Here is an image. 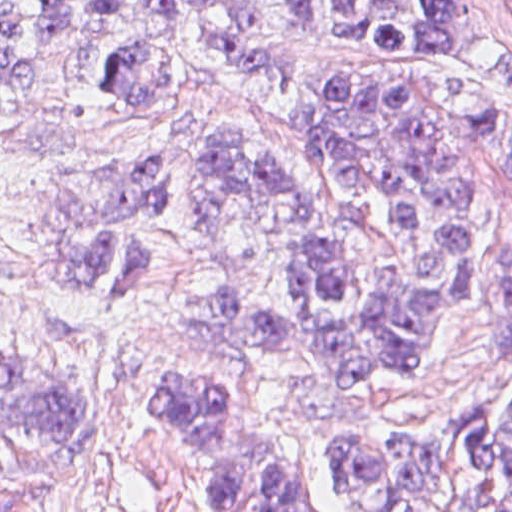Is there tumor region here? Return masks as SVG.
I'll use <instances>...</instances> for the list:
<instances>
[{
	"mask_svg": "<svg viewBox=\"0 0 512 512\" xmlns=\"http://www.w3.org/2000/svg\"><path fill=\"white\" fill-rule=\"evenodd\" d=\"M501 1L512 16V0ZM177 10L215 57L277 77L297 65L285 22L321 42L431 57L480 138L512 168V118L455 63L466 0H334L328 27L319 0H0V109L30 89L43 58L75 30L104 39L99 71L112 90L131 99L161 95L177 73L169 33ZM295 127L334 177L384 198L419 241L422 272L399 278L384 303L365 302L352 254L316 196L268 152L220 135L209 143L198 220L222 230L241 206H257L296 302L284 306L234 279L206 294L189 290L177 309L183 355L328 377H382L429 363L424 342L445 311L464 303L469 257V200L443 117L386 78L340 70L323 75ZM170 174L171 165L143 159L60 175L37 217V265L48 282L90 295L150 267L122 234L154 221V198ZM501 299L500 349H512V248L501 264ZM157 391L213 512H324L246 378L213 363H172L157 370ZM94 395L107 403L71 371L0 353V415L77 451ZM318 473L343 512H437L452 493L473 512H512V398L500 414L491 402L474 408L441 440L358 421L321 424Z\"/></svg>",
	"mask_w": 512,
	"mask_h": 512,
	"instance_id": "obj_1",
	"label": "tumor region"
}]
</instances>
